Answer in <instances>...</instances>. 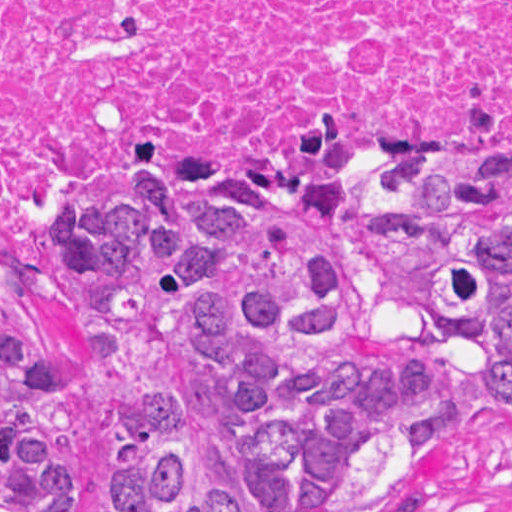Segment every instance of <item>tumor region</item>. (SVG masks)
Wrapping results in <instances>:
<instances>
[{"mask_svg":"<svg viewBox=\"0 0 512 512\" xmlns=\"http://www.w3.org/2000/svg\"><path fill=\"white\" fill-rule=\"evenodd\" d=\"M53 222L96 379L99 512L424 508L415 475L467 388L432 350L378 347L340 173L168 176L56 199ZM353 240L388 306L478 351L485 408L512 423V173H366ZM38 331L0 312V512H82Z\"/></svg>","mask_w":512,"mask_h":512,"instance_id":"1","label":"tumor region"}]
</instances>
